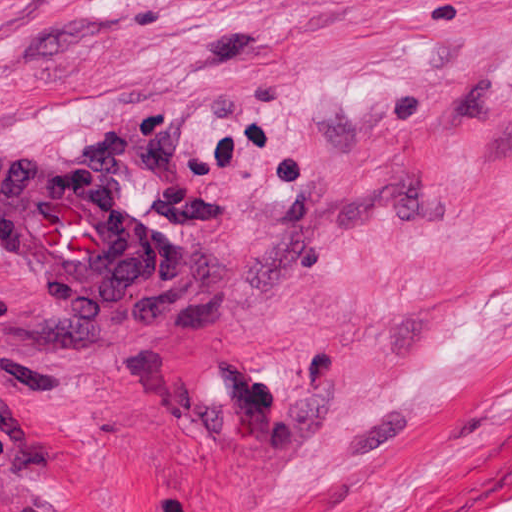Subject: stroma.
I'll return each mask as SVG.
<instances>
[{
    "mask_svg": "<svg viewBox=\"0 0 512 512\" xmlns=\"http://www.w3.org/2000/svg\"><path fill=\"white\" fill-rule=\"evenodd\" d=\"M0 153L137 224L0 251V512H512V0H0Z\"/></svg>",
    "mask_w": 512,
    "mask_h": 512,
    "instance_id": "35a3bbf8",
    "label": "stroma"
}]
</instances>
